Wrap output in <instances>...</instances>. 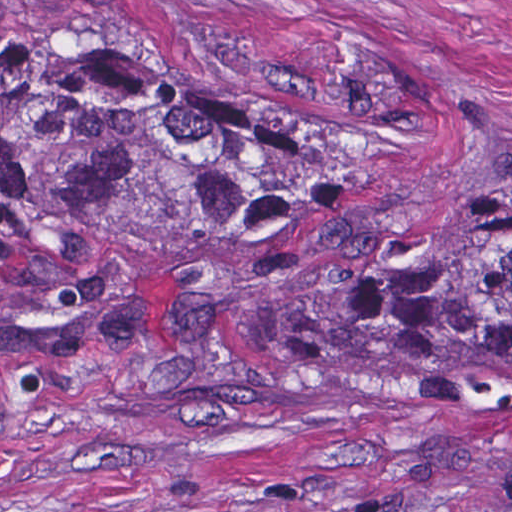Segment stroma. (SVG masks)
<instances>
[{
	"mask_svg": "<svg viewBox=\"0 0 512 512\" xmlns=\"http://www.w3.org/2000/svg\"><path fill=\"white\" fill-rule=\"evenodd\" d=\"M122 47L349 132L380 282L512 200V0H0V512H512V359L281 332L171 256L1 340V39Z\"/></svg>",
	"mask_w": 512,
	"mask_h": 512,
	"instance_id": "35a3bbf8",
	"label": "stroma"
}]
</instances>
